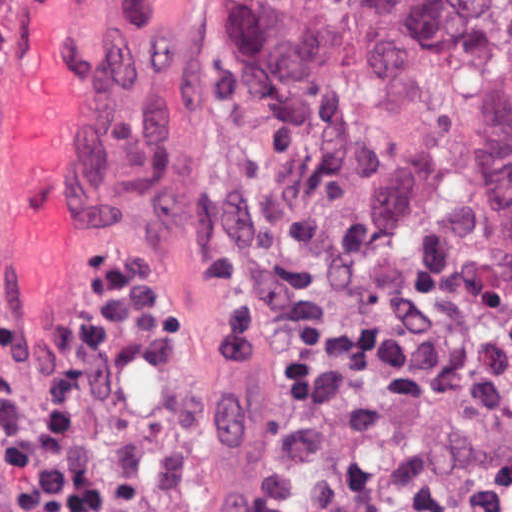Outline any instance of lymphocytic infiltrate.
Instances as JSON below:
<instances>
[{"instance_id": "f902f5d3", "label": "lymphocytic infiltrate", "mask_w": 512, "mask_h": 512, "mask_svg": "<svg viewBox=\"0 0 512 512\" xmlns=\"http://www.w3.org/2000/svg\"><path fill=\"white\" fill-rule=\"evenodd\" d=\"M118 256L75 298L44 355L17 309L0 328V435L16 510L98 512L102 483L88 449L138 325L155 303L151 279ZM274 387L287 388L265 376Z\"/></svg>"}]
</instances>
